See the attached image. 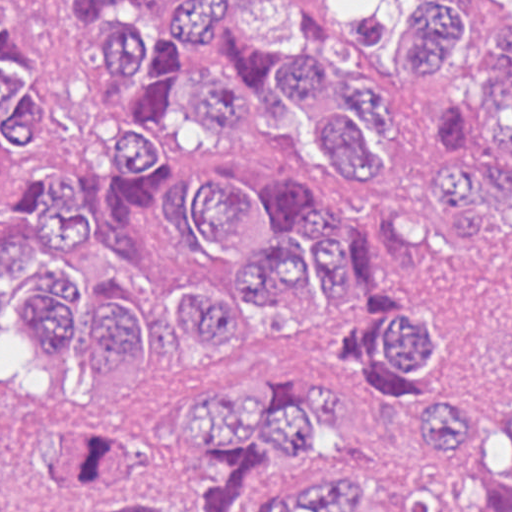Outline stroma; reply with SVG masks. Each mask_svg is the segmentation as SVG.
I'll return each mask as SVG.
<instances>
[{"label": "stroma", "instance_id": "obj_1", "mask_svg": "<svg viewBox=\"0 0 512 512\" xmlns=\"http://www.w3.org/2000/svg\"><path fill=\"white\" fill-rule=\"evenodd\" d=\"M161 1L104 0L100 10L134 35L154 29ZM365 2L322 0L312 22L331 75L361 81L387 98L390 129L362 131L381 169L369 184L342 179L322 136L280 90L266 87L258 118L246 127L208 130L194 117L191 78L211 67L228 41L182 53L176 103L157 141L167 172L129 213L132 247L161 286L218 289L208 273L191 267L174 232L172 182L195 162L225 168L247 191H266L276 179L302 183L332 223L358 228L397 217L420 201L447 141L432 134L429 119L438 104L482 92L485 45L512 21V0H456L468 31L455 62L433 79L398 74L392 45L371 56L354 52L346 20L359 15ZM14 35L32 55L45 100L42 131L16 167L14 185L30 191L75 179L85 207L103 211L117 167L114 133L133 109L131 82L105 73L97 50L79 43L55 0H20ZM485 217L484 236L466 247L456 214L442 203H418L393 223L399 296L425 311L436 338V360L414 381H390L368 360L367 334L377 314L374 298L358 284L320 311L243 338L225 357L204 355L176 317L161 311L147 319L141 348L121 377H85L74 345L59 339L48 351L37 350L62 371L60 398L21 401L1 383V327L23 325L1 324L0 0V512H78L66 488L43 471L46 422L66 415L109 419L123 433L130 459L144 465L162 452V398L244 377H275L301 387L326 378L343 387L347 423L331 429L324 444L333 464L407 488L427 471L412 451L418 399L462 394L487 407L512 404V205L488 201Z\"/></svg>", "mask_w": 512, "mask_h": 512}]
</instances>
